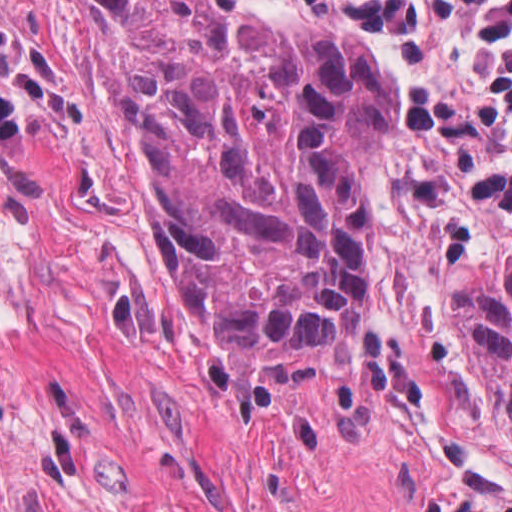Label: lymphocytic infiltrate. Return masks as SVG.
Returning a JSON list of instances; mask_svg holds the SVG:
<instances>
[{"label": "lymphocytic infiltrate", "mask_w": 512, "mask_h": 512, "mask_svg": "<svg viewBox=\"0 0 512 512\" xmlns=\"http://www.w3.org/2000/svg\"><path fill=\"white\" fill-rule=\"evenodd\" d=\"M472 14L491 50L493 70L485 105L474 109L444 96L418 91L405 117L422 133L469 144L487 132L495 145L467 175L441 182L425 173L402 175L398 185L423 200L434 214L436 247L443 262H458L477 238L480 208L512 213V0H350L341 7L345 24L384 39L398 63L423 65L439 13Z\"/></svg>", "instance_id": "lymphocytic-infiltrate-1"}]
</instances>
